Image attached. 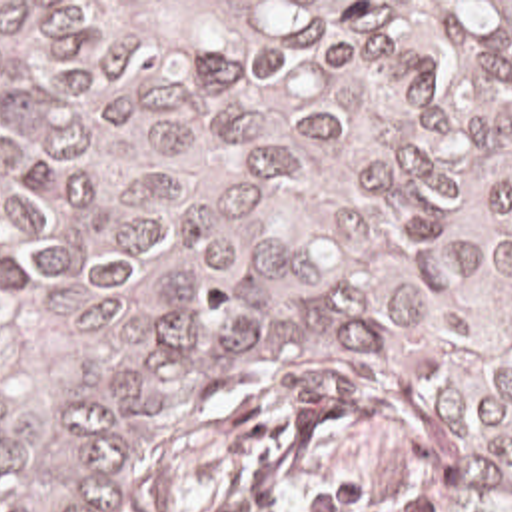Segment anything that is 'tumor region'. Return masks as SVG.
<instances>
[{
	"mask_svg": "<svg viewBox=\"0 0 512 512\" xmlns=\"http://www.w3.org/2000/svg\"><path fill=\"white\" fill-rule=\"evenodd\" d=\"M286 371L404 425L320 512H512V2H0V512Z\"/></svg>",
	"mask_w": 512,
	"mask_h": 512,
	"instance_id": "1",
	"label": "tumor region"
}]
</instances>
